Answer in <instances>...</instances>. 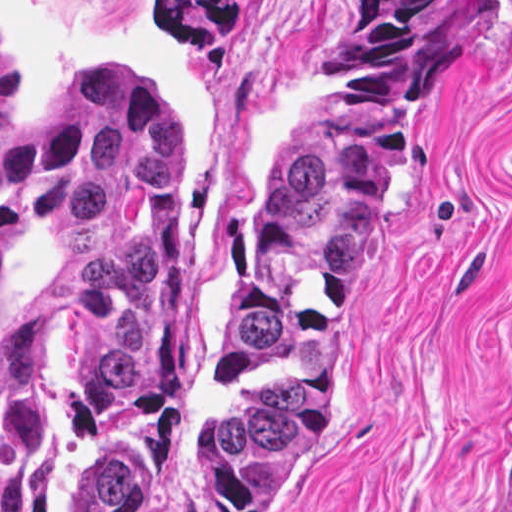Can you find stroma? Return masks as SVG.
Instances as JSON below:
<instances>
[{
  "label": "stroma",
  "instance_id": "stroma-1",
  "mask_svg": "<svg viewBox=\"0 0 512 512\" xmlns=\"http://www.w3.org/2000/svg\"><path fill=\"white\" fill-rule=\"evenodd\" d=\"M233 1L239 22L184 46L166 0H0L17 119L51 116L72 73L98 63H143L178 118L200 407L178 446L171 512H225L218 330L347 0ZM510 499L512 0H467L429 56L358 274L324 434L281 512H497ZM28 512H66L64 426L46 405L28 412Z\"/></svg>",
  "mask_w": 512,
  "mask_h": 512
}]
</instances>
